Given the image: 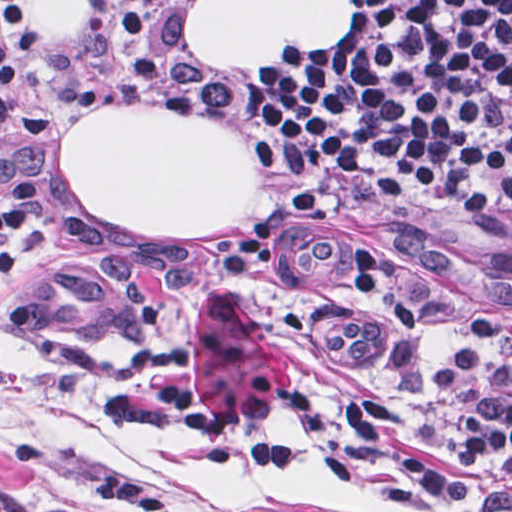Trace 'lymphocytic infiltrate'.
Here are the masks:
<instances>
[{
  "label": "lymphocytic infiltrate",
  "instance_id": "f902f5d3",
  "mask_svg": "<svg viewBox=\"0 0 512 512\" xmlns=\"http://www.w3.org/2000/svg\"><path fill=\"white\" fill-rule=\"evenodd\" d=\"M357 31L295 70H240V97L277 160L327 185L402 201L448 223L512 232V0H360ZM113 39L82 103L105 116L161 95L157 0H111ZM42 49L39 0H0V143L26 112V76ZM48 188L0 186V272L24 259ZM323 208L303 188L263 214L224 262L244 274L275 257L274 234ZM360 300L407 337H438L435 385L455 403L466 457L491 482L458 477L395 391L354 399L341 444L258 441L193 401L169 374L151 391L195 466L311 472L361 455L424 495L472 512H512V360L418 303L379 246L350 245Z\"/></svg>",
  "mask_w": 512,
  "mask_h": 512
}]
</instances>
